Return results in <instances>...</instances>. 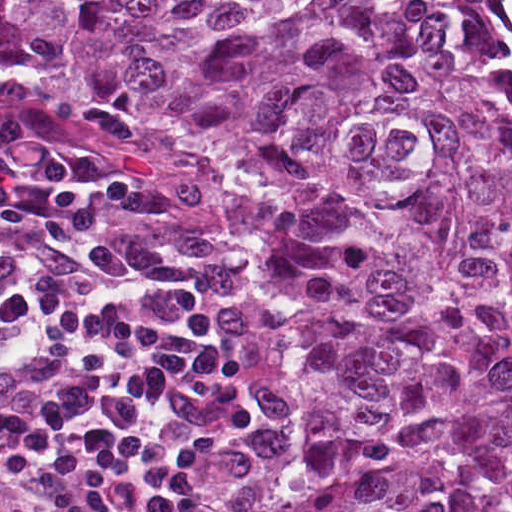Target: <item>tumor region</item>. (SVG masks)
<instances>
[{
    "label": "tumor region",
    "instance_id": "e687c5a6",
    "mask_svg": "<svg viewBox=\"0 0 512 512\" xmlns=\"http://www.w3.org/2000/svg\"><path fill=\"white\" fill-rule=\"evenodd\" d=\"M0 58L187 147L306 358L270 512H512V124L437 0H0Z\"/></svg>",
    "mask_w": 512,
    "mask_h": 512
}]
</instances>
